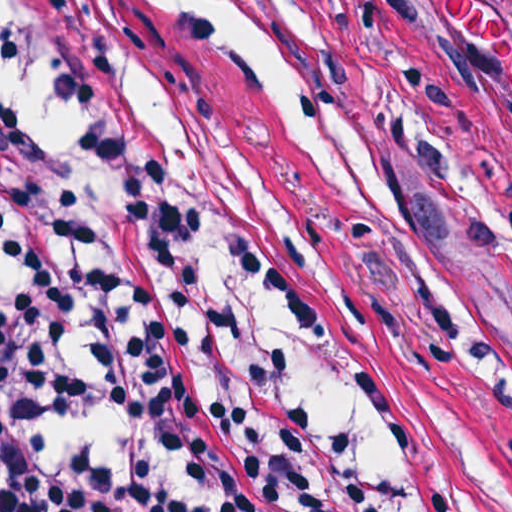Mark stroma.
Instances as JSON below:
<instances>
[{
  "label": "stroma",
  "instance_id": "35a3bbf8",
  "mask_svg": "<svg viewBox=\"0 0 512 512\" xmlns=\"http://www.w3.org/2000/svg\"><path fill=\"white\" fill-rule=\"evenodd\" d=\"M107 119L143 238L200 375L311 512H471L469 434L422 336L360 309L338 325L372 429L342 439L207 216L155 88L160 0H47ZM372 182L378 212L512 336V245L472 197L494 160L373 0H283Z\"/></svg>",
  "mask_w": 512,
  "mask_h": 512
}]
</instances>
